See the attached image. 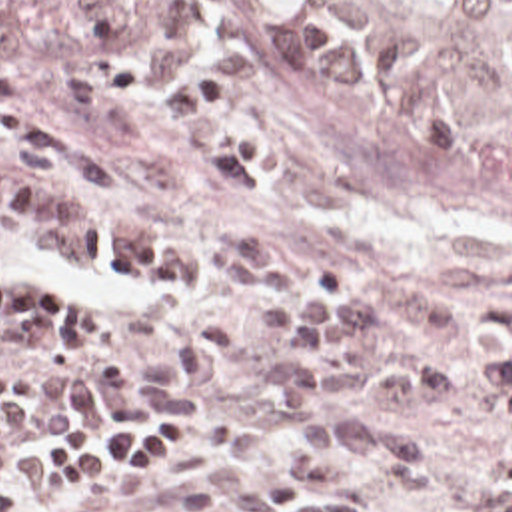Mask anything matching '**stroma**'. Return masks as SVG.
<instances>
[{"label":"stroma","instance_id":"obj_1","mask_svg":"<svg viewBox=\"0 0 512 512\" xmlns=\"http://www.w3.org/2000/svg\"><path fill=\"white\" fill-rule=\"evenodd\" d=\"M157 26L185 65L225 81L217 113L265 137L257 177L263 199H245L207 163L199 139L173 111V67L143 39V79L99 113L75 109L63 91L75 65L87 81L103 39L73 0H0V95L57 119L99 155L111 193L59 179L47 193L77 217L205 255L185 289H131L77 271L25 239L0 237V279L63 283V323L27 343H0V377L87 371L111 353L147 371L175 361L185 339L205 337L203 317L237 327V367L207 391L209 413L179 425V449L149 479L47 485L39 441L17 512H65L83 501L137 512L177 501L199 512H233L237 491L277 467L289 423L319 411L409 417L359 395L319 411L275 397L273 335L249 323L247 297L211 281L219 235L249 229L285 263H315L349 287L403 285L419 293L397 351L401 359H481L512 333V173L437 159L383 141L349 117L297 65L275 0H161ZM269 179H265L263 175ZM399 427L429 441L439 477L423 493L397 487L375 457L345 455L343 481L325 493L355 501L351 512L463 511L512 493L497 483L499 421L469 401H431Z\"/></svg>","mask_w":512,"mask_h":512}]
</instances>
